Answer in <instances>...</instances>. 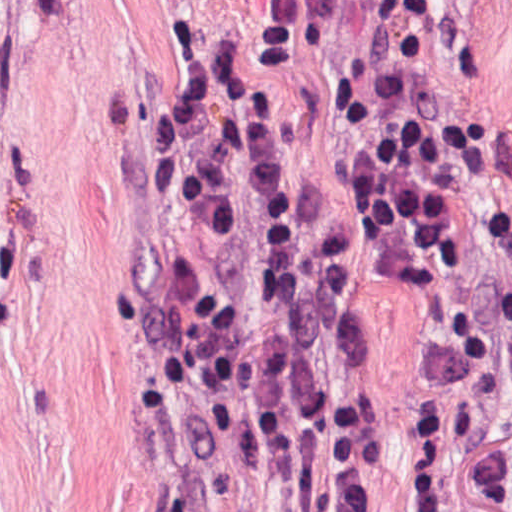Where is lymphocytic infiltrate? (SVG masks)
<instances>
[{
  "label": "lymphocytic infiltrate",
  "mask_w": 512,
  "mask_h": 512,
  "mask_svg": "<svg viewBox=\"0 0 512 512\" xmlns=\"http://www.w3.org/2000/svg\"><path fill=\"white\" fill-rule=\"evenodd\" d=\"M174 5L180 86L139 141L158 258L120 333L146 470L171 512H373L384 443L359 370L354 211L410 295L503 250L510 214L409 35L339 94L350 203Z\"/></svg>",
  "instance_id": "f902f5d3"
}]
</instances>
